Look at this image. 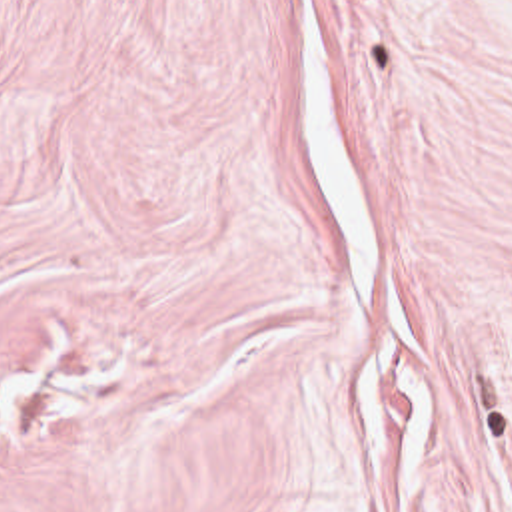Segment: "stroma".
Instances as JSON below:
<instances>
[{"label":"stroma","instance_id":"stroma-1","mask_svg":"<svg viewBox=\"0 0 512 512\" xmlns=\"http://www.w3.org/2000/svg\"><path fill=\"white\" fill-rule=\"evenodd\" d=\"M0 512H512V0H0Z\"/></svg>","mask_w":512,"mask_h":512}]
</instances>
